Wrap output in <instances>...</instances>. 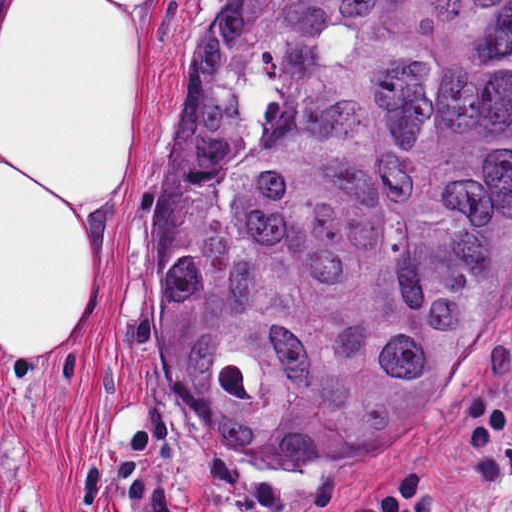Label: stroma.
<instances>
[{
  "label": "stroma",
  "instance_id": "stroma-1",
  "mask_svg": "<svg viewBox=\"0 0 512 512\" xmlns=\"http://www.w3.org/2000/svg\"><path fill=\"white\" fill-rule=\"evenodd\" d=\"M28 1L0 0V66ZM226 1L178 0L172 11L99 315L58 360H0V512H342L397 452L418 445L453 472L452 512H512L500 440L470 447L469 402L461 411L464 396H485L512 417V271L475 352L393 446L272 464L202 430L177 401L158 351L152 222L186 121L188 69Z\"/></svg>",
  "mask_w": 512,
  "mask_h": 512
}]
</instances>
